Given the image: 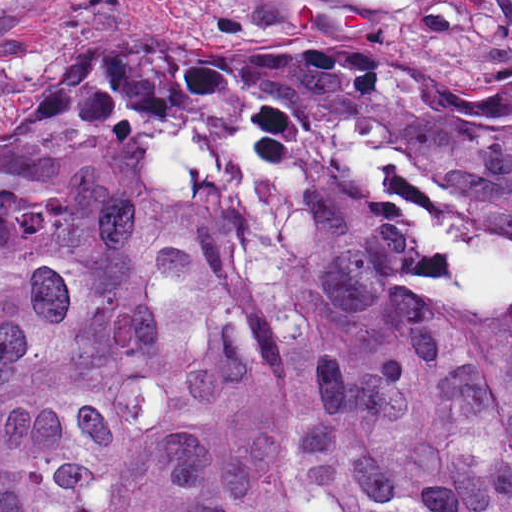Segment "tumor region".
Returning <instances> with one entry per match:
<instances>
[{"instance_id": "e687c5a6", "label": "tumor region", "mask_w": 512, "mask_h": 512, "mask_svg": "<svg viewBox=\"0 0 512 512\" xmlns=\"http://www.w3.org/2000/svg\"><path fill=\"white\" fill-rule=\"evenodd\" d=\"M245 55L0 145V512H512V74Z\"/></svg>"}]
</instances>
